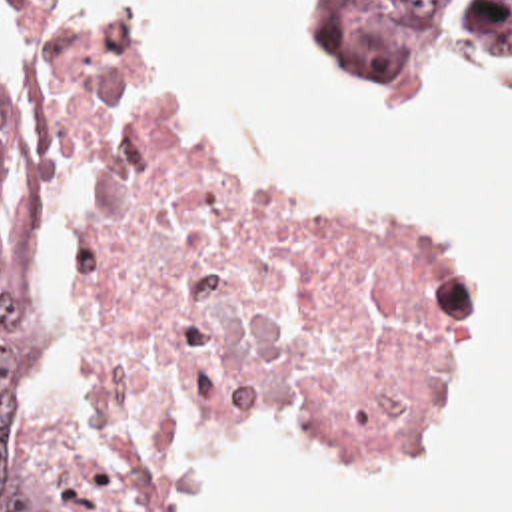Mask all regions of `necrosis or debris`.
Returning a JSON list of instances; mask_svg holds the SVG:
<instances>
[{
	"label": "necrosis or debris",
	"instance_id": "necrosis-or-debris-1",
	"mask_svg": "<svg viewBox=\"0 0 512 512\" xmlns=\"http://www.w3.org/2000/svg\"><path fill=\"white\" fill-rule=\"evenodd\" d=\"M25 7V65L63 141L134 103L77 225L85 462L101 512H154L198 434L266 403L364 428L424 419L450 345V269L266 187L206 149L142 69Z\"/></svg>",
	"mask_w": 512,
	"mask_h": 512
}]
</instances>
